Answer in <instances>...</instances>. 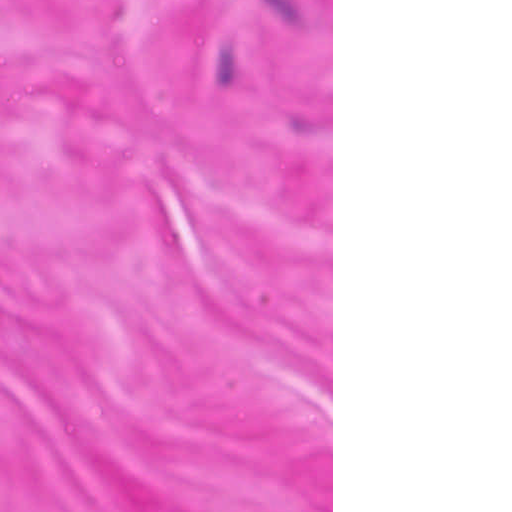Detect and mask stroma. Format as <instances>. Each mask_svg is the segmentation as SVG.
Segmentation results:
<instances>
[{"mask_svg": "<svg viewBox=\"0 0 512 512\" xmlns=\"http://www.w3.org/2000/svg\"><path fill=\"white\" fill-rule=\"evenodd\" d=\"M0 512H333V0H0Z\"/></svg>", "mask_w": 512, "mask_h": 512, "instance_id": "35a3bbf8", "label": "stroma"}]
</instances>
